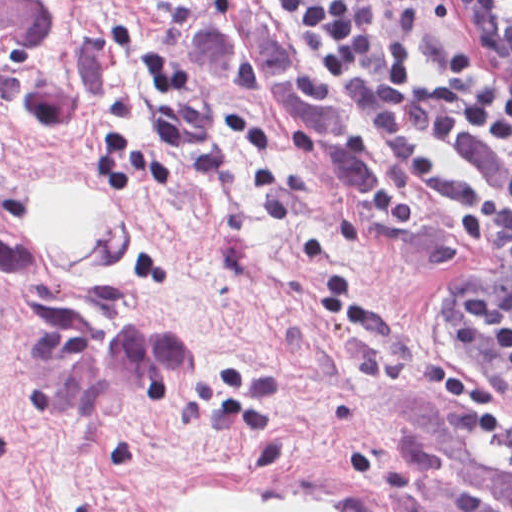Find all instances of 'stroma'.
I'll list each match as a JSON object with an SVG mask.
<instances>
[{
    "label": "stroma",
    "mask_w": 512,
    "mask_h": 512,
    "mask_svg": "<svg viewBox=\"0 0 512 512\" xmlns=\"http://www.w3.org/2000/svg\"><path fill=\"white\" fill-rule=\"evenodd\" d=\"M54 1L80 107L33 120L0 88V512H182L209 488L414 512L386 406L437 401L425 369L457 365L447 309L490 253L424 204L400 230L375 222L386 144L271 0L254 2L278 40L380 156L371 196L275 102L196 85L198 0ZM441 43L512 80V33L413 0L412 54ZM52 176L112 199L134 226L128 262L59 270L26 217ZM486 423L512 446V425Z\"/></svg>",
    "instance_id": "1"
}]
</instances>
